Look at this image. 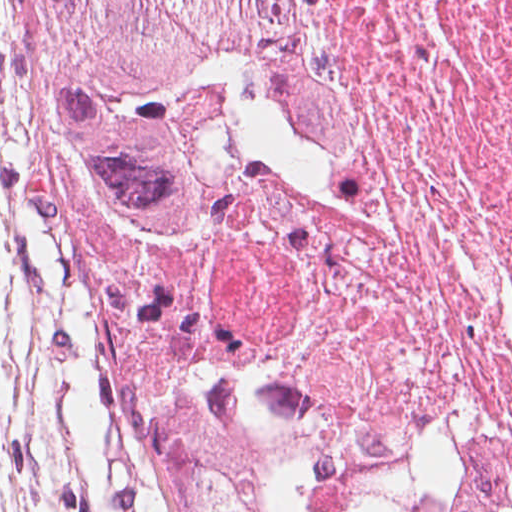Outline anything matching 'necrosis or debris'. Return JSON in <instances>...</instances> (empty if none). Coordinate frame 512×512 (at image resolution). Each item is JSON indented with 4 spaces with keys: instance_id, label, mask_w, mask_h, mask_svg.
Wrapping results in <instances>:
<instances>
[{
    "instance_id": "4bbe7bcc",
    "label": "necrosis or debris",
    "mask_w": 512,
    "mask_h": 512,
    "mask_svg": "<svg viewBox=\"0 0 512 512\" xmlns=\"http://www.w3.org/2000/svg\"><path fill=\"white\" fill-rule=\"evenodd\" d=\"M354 142L216 198L190 299L281 512H512V0H296Z\"/></svg>"
}]
</instances>
